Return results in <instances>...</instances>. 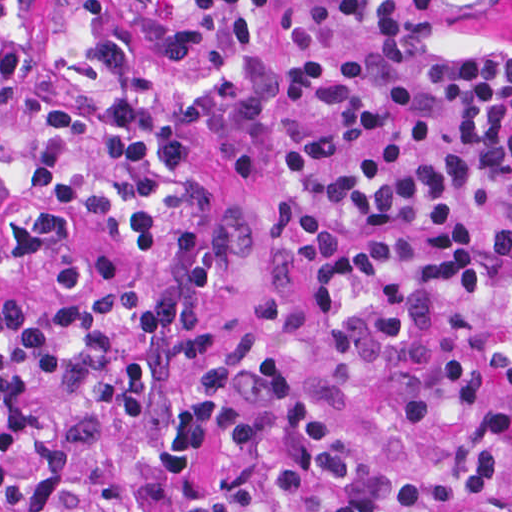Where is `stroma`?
Instances as JSON below:
<instances>
[{
	"label": "stroma",
	"mask_w": 512,
	"mask_h": 512,
	"mask_svg": "<svg viewBox=\"0 0 512 512\" xmlns=\"http://www.w3.org/2000/svg\"><path fill=\"white\" fill-rule=\"evenodd\" d=\"M103 24L143 60L154 74L158 107L165 126L189 151L210 200L194 226V238L209 241L234 205L248 197L246 185L225 163L216 137L200 121L184 113L222 66V44L214 37L184 65L155 53L141 25L109 0H93ZM29 61L50 66L48 13L45 0H29L26 15ZM512 45V0H442L436 12L435 34L420 72L448 64L462 52L490 42Z\"/></svg>",
	"instance_id": "obj_1"
}]
</instances>
